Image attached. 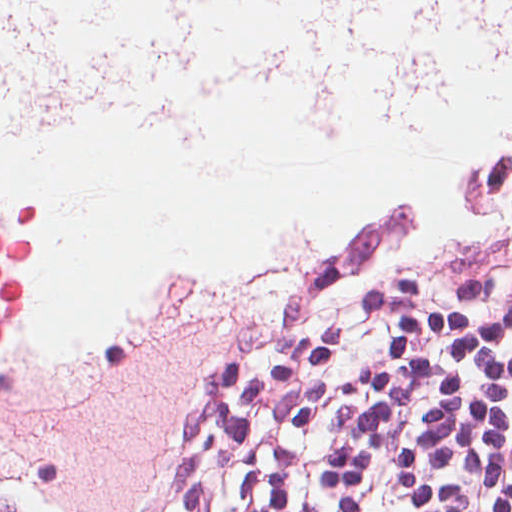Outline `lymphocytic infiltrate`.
<instances>
[{"mask_svg": "<svg viewBox=\"0 0 512 512\" xmlns=\"http://www.w3.org/2000/svg\"><path fill=\"white\" fill-rule=\"evenodd\" d=\"M491 223L374 214L278 269L106 512H512V282L433 278Z\"/></svg>", "mask_w": 512, "mask_h": 512, "instance_id": "f902f5d3", "label": "lymphocytic infiltrate"}]
</instances>
